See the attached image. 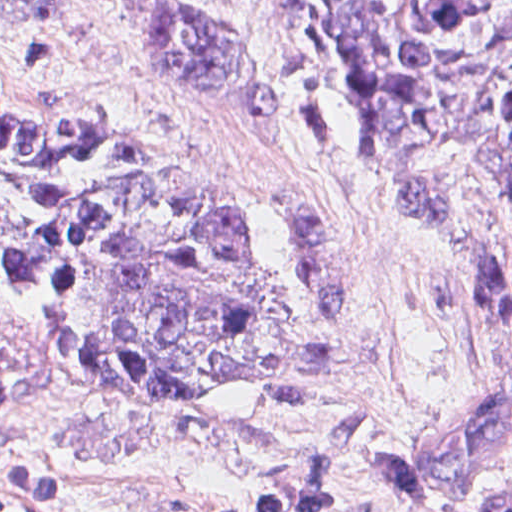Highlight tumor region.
Returning <instances> with one entry per match:
<instances>
[{
  "mask_svg": "<svg viewBox=\"0 0 512 512\" xmlns=\"http://www.w3.org/2000/svg\"><path fill=\"white\" fill-rule=\"evenodd\" d=\"M157 87L271 119V68L185 0H126ZM354 142L388 161L444 147L512 200L510 0H288ZM42 20V27H24ZM53 0H0L44 31ZM49 304L69 368L200 396L274 376L292 345V262L253 201L197 166L0 91V292ZM512 453V385L451 407L409 450V501L467 492ZM489 512H512L509 497Z\"/></svg>",
  "mask_w": 512,
  "mask_h": 512,
  "instance_id": "1",
  "label": "tumor region"
}]
</instances>
